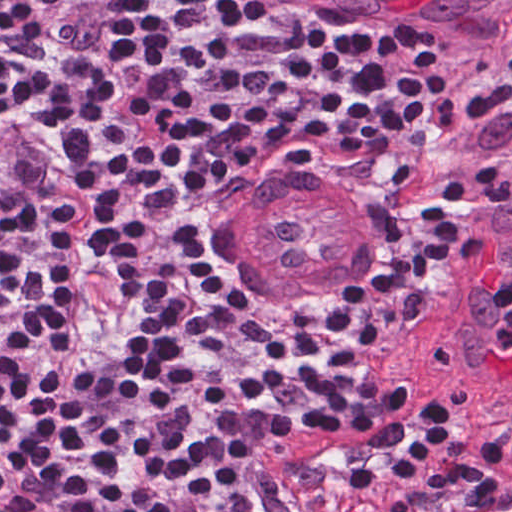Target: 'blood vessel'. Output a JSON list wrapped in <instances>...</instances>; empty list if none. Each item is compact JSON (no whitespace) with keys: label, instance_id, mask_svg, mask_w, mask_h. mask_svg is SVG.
I'll list each match as a JSON object with an SVG mask.
<instances>
[{"label":"blood vessel","instance_id":"blood-vessel-1","mask_svg":"<svg viewBox=\"0 0 512 512\" xmlns=\"http://www.w3.org/2000/svg\"><path fill=\"white\" fill-rule=\"evenodd\" d=\"M361 2L459 25L512 21V0H330L308 8L324 14ZM248 186L261 190L224 178L210 196L199 238L207 274L244 306H273L323 289L356 250L341 202L302 178ZM505 279L512 290L509 234L473 262L446 299L445 359L478 389L512 390V350L494 342L500 315L493 294Z\"/></svg>","mask_w":512,"mask_h":512}]
</instances>
